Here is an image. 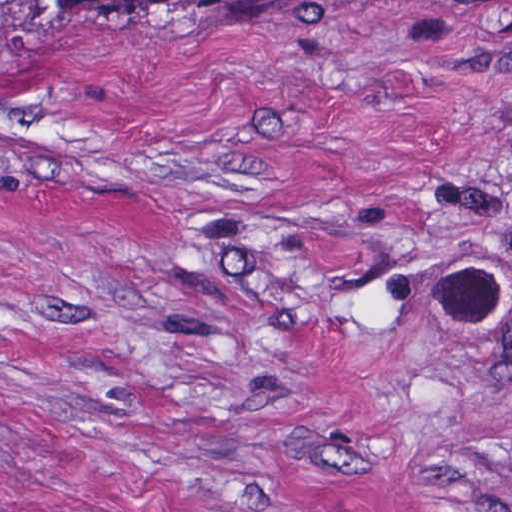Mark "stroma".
<instances>
[{"mask_svg": "<svg viewBox=\"0 0 512 512\" xmlns=\"http://www.w3.org/2000/svg\"><path fill=\"white\" fill-rule=\"evenodd\" d=\"M0 512H512V0L16 40Z\"/></svg>", "mask_w": 512, "mask_h": 512, "instance_id": "1", "label": "stroma"}]
</instances>
